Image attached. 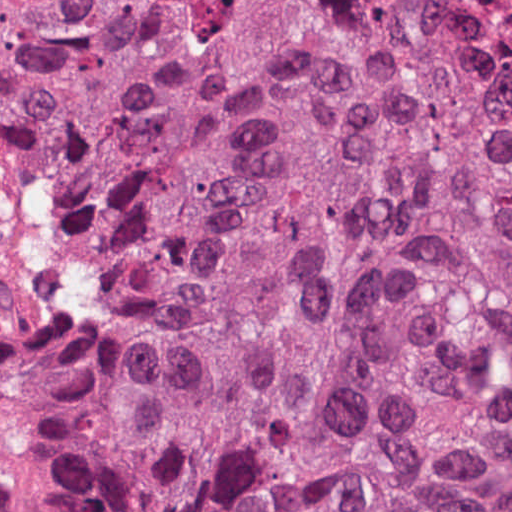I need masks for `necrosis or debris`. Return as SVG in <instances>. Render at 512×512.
<instances>
[{
  "mask_svg": "<svg viewBox=\"0 0 512 512\" xmlns=\"http://www.w3.org/2000/svg\"><path fill=\"white\" fill-rule=\"evenodd\" d=\"M400 2H423L442 6H475L501 0H397Z\"/></svg>",
  "mask_w": 512,
  "mask_h": 512,
  "instance_id": "necrosis-or-debris-1",
  "label": "necrosis or debris"
}]
</instances>
